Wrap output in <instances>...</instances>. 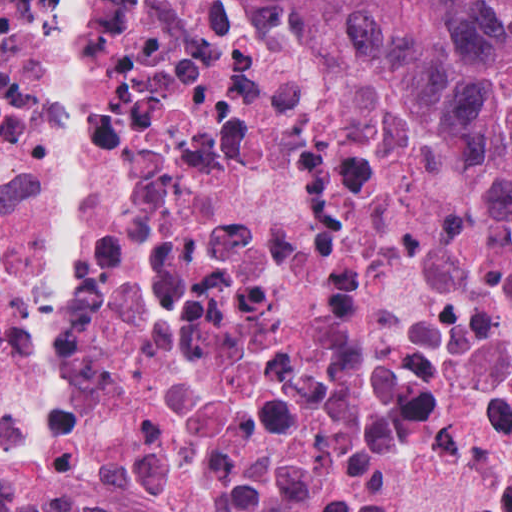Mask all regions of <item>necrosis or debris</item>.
<instances>
[{"instance_id": "1", "label": "necrosis or debris", "mask_w": 512, "mask_h": 512, "mask_svg": "<svg viewBox=\"0 0 512 512\" xmlns=\"http://www.w3.org/2000/svg\"><path fill=\"white\" fill-rule=\"evenodd\" d=\"M0 512H512V243L426 60L0 0Z\"/></svg>"}]
</instances>
